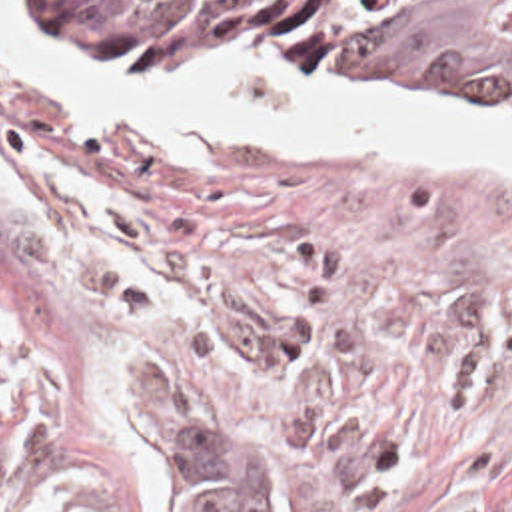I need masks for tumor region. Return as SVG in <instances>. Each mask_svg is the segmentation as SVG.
Wrapping results in <instances>:
<instances>
[{
	"mask_svg": "<svg viewBox=\"0 0 512 512\" xmlns=\"http://www.w3.org/2000/svg\"><path fill=\"white\" fill-rule=\"evenodd\" d=\"M97 65L139 79H215L263 55H322L418 103L512 113V0H47ZM17 371L0 345V399ZM171 393L133 429L163 512H273V483L209 439ZM73 512H117L83 507Z\"/></svg>",
	"mask_w": 512,
	"mask_h": 512,
	"instance_id": "e687c5a6",
	"label": "tumor region"
}]
</instances>
